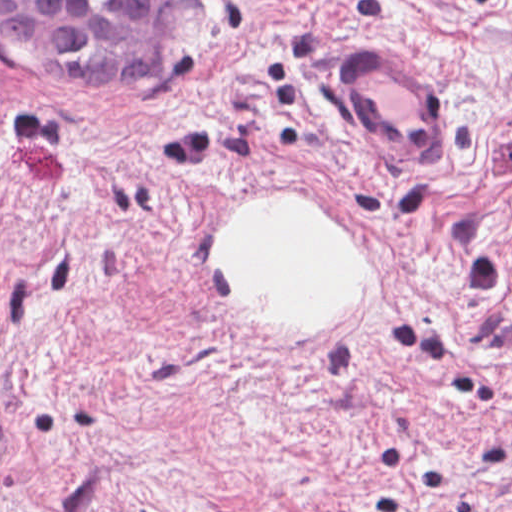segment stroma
I'll return each mask as SVG.
<instances>
[{
  "label": "stroma",
  "instance_id": "35a3bbf8",
  "mask_svg": "<svg viewBox=\"0 0 512 512\" xmlns=\"http://www.w3.org/2000/svg\"><path fill=\"white\" fill-rule=\"evenodd\" d=\"M0 1H171L155 82L0 49V512H512V0ZM359 42L436 94V165L353 138ZM260 193L366 259L351 325L220 297Z\"/></svg>",
  "mask_w": 512,
  "mask_h": 512
}]
</instances>
